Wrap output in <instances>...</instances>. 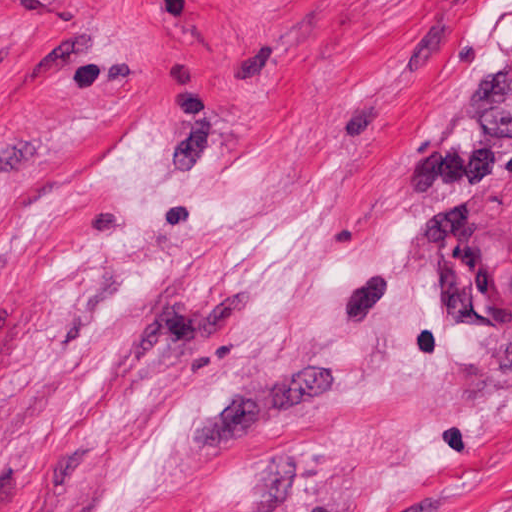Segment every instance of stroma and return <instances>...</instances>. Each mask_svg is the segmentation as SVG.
<instances>
[{
	"instance_id": "35a3bbf8",
	"label": "stroma",
	"mask_w": 512,
	"mask_h": 512,
	"mask_svg": "<svg viewBox=\"0 0 512 512\" xmlns=\"http://www.w3.org/2000/svg\"><path fill=\"white\" fill-rule=\"evenodd\" d=\"M0 512H512V0H0Z\"/></svg>"
}]
</instances>
